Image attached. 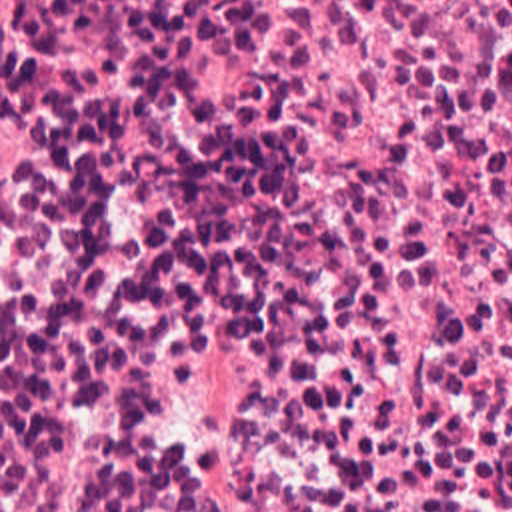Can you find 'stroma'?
<instances>
[{"label": "stroma", "instance_id": "35a3bbf8", "mask_svg": "<svg viewBox=\"0 0 512 512\" xmlns=\"http://www.w3.org/2000/svg\"><path fill=\"white\" fill-rule=\"evenodd\" d=\"M0 512H512V428H0Z\"/></svg>", "mask_w": 512, "mask_h": 512}]
</instances>
